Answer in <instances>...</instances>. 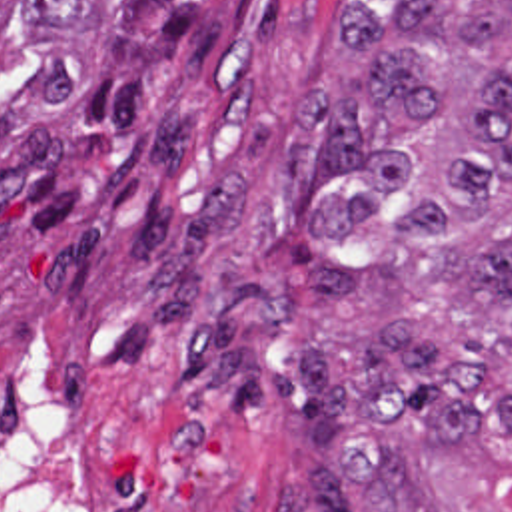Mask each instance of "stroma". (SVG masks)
Wrapping results in <instances>:
<instances>
[{
	"instance_id": "obj_1",
	"label": "stroma",
	"mask_w": 512,
	"mask_h": 512,
	"mask_svg": "<svg viewBox=\"0 0 512 512\" xmlns=\"http://www.w3.org/2000/svg\"><path fill=\"white\" fill-rule=\"evenodd\" d=\"M398 0H0V342L66 382L96 512H276L318 470L286 402L232 408L182 358L224 289L292 318L262 356L352 338L316 302V187L280 185L296 97L356 95L370 55L340 11Z\"/></svg>"
}]
</instances>
